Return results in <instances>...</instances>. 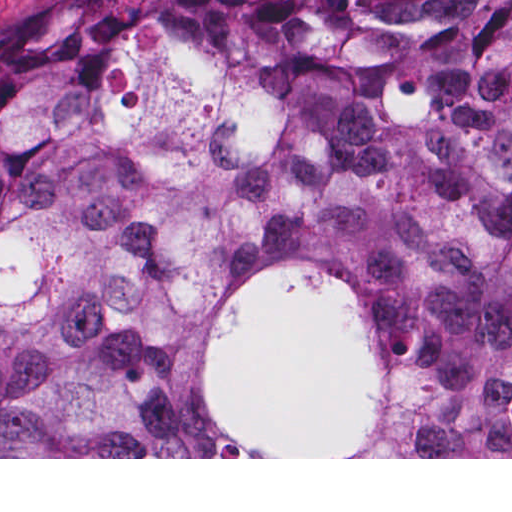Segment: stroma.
I'll return each mask as SVG.
<instances>
[{"label": "stroma", "instance_id": "1", "mask_svg": "<svg viewBox=\"0 0 512 512\" xmlns=\"http://www.w3.org/2000/svg\"><path fill=\"white\" fill-rule=\"evenodd\" d=\"M38 0H0V18ZM208 424L260 457L0 459H512L357 457L383 435L388 393L366 301L306 271L234 289L194 367Z\"/></svg>", "mask_w": 512, "mask_h": 512}]
</instances>
